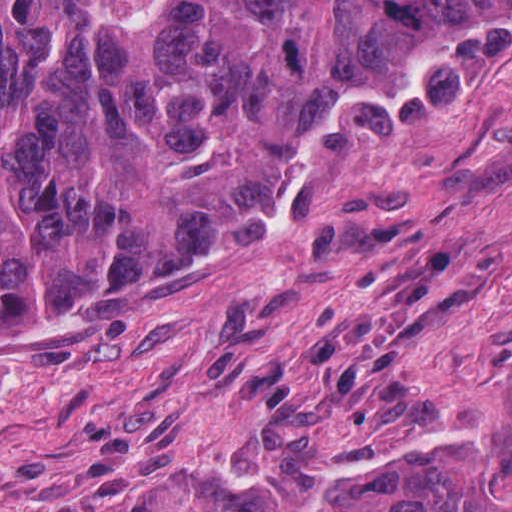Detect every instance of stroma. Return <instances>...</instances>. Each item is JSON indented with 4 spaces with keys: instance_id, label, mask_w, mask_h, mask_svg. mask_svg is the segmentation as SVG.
<instances>
[{
    "instance_id": "1",
    "label": "stroma",
    "mask_w": 512,
    "mask_h": 512,
    "mask_svg": "<svg viewBox=\"0 0 512 512\" xmlns=\"http://www.w3.org/2000/svg\"><path fill=\"white\" fill-rule=\"evenodd\" d=\"M512 1V0H0ZM512 410V23L317 114L278 211L0 329V512L302 477Z\"/></svg>"
}]
</instances>
